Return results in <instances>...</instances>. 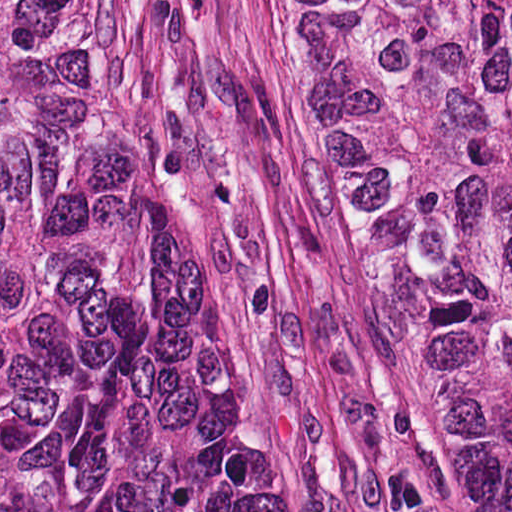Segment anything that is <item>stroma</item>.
I'll use <instances>...</instances> for the list:
<instances>
[{"label":"stroma","instance_id":"1","mask_svg":"<svg viewBox=\"0 0 512 512\" xmlns=\"http://www.w3.org/2000/svg\"><path fill=\"white\" fill-rule=\"evenodd\" d=\"M119 1L308 511L450 512L418 362L320 184L298 0Z\"/></svg>","mask_w":512,"mask_h":512}]
</instances>
